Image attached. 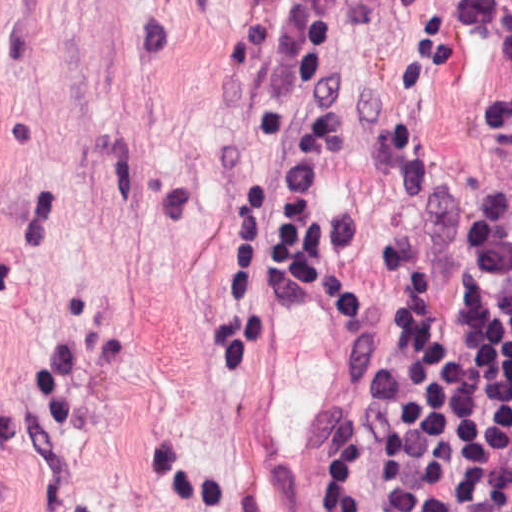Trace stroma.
Masks as SVG:
<instances>
[{
  "instance_id": "obj_1",
  "label": "stroma",
  "mask_w": 512,
  "mask_h": 512,
  "mask_svg": "<svg viewBox=\"0 0 512 512\" xmlns=\"http://www.w3.org/2000/svg\"><path fill=\"white\" fill-rule=\"evenodd\" d=\"M288 1L0 0V512H313L394 250L512 129V0H341L342 331L264 262ZM317 512H382L374 467Z\"/></svg>"
}]
</instances>
